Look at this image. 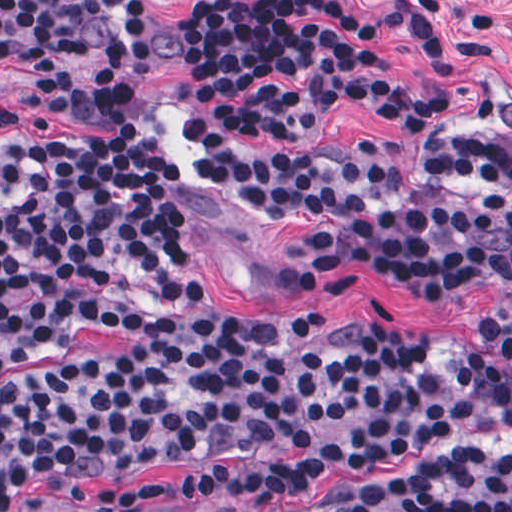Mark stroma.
<instances>
[{
  "label": "stroma",
  "instance_id": "obj_1",
  "mask_svg": "<svg viewBox=\"0 0 512 512\" xmlns=\"http://www.w3.org/2000/svg\"><path fill=\"white\" fill-rule=\"evenodd\" d=\"M127 1L154 12L155 49L144 59H96L16 69L0 78V113L50 136H71L80 126L57 119L22 91L39 77L124 75L153 80L143 101L146 115L169 134L177 150L182 184L189 196L172 227L201 251V272L217 308L255 330L232 343L249 345L273 325H305L332 319L363 325H413L444 331H476L483 318L495 323L512 356V297L427 281L380 266H328L275 240L248 221L207 182L178 121V84L193 74L195 17L201 1H457L442 20L458 41H482L491 57L458 74L434 73L419 38L404 25L386 27L382 39L397 83L408 89L439 91L449 102L407 130L380 122L352 106L325 110L306 138L323 157L340 155L359 142L374 140L393 171L426 165L456 136L512 142V0H0ZM128 352L114 329L76 336L63 350L25 365L0 369V389L91 359ZM512 448V436L489 437L438 447L362 477H336L306 495H292L268 510L217 496L195 500L183 492L189 465H141L138 483L165 482L171 496L130 512H344L368 488L401 479L420 467L464 451ZM102 484L91 483L75 504L63 483L45 477L13 501L6 512H99Z\"/></svg>",
  "mask_w": 512,
  "mask_h": 512
}]
</instances>
